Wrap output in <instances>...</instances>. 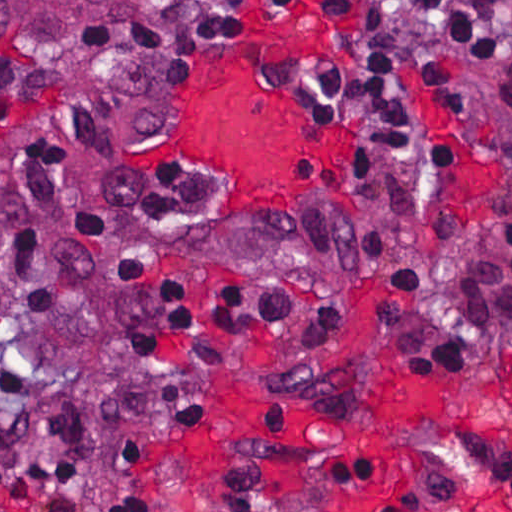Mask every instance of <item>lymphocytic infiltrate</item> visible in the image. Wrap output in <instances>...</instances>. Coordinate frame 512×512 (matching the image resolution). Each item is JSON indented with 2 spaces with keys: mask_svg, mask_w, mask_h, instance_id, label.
<instances>
[{
  "mask_svg": "<svg viewBox=\"0 0 512 512\" xmlns=\"http://www.w3.org/2000/svg\"><path fill=\"white\" fill-rule=\"evenodd\" d=\"M297 0H218L189 25L169 36L153 53L124 71L111 90L126 97L139 129H151L164 116L160 96L139 75L141 62H154L169 81H179L201 48L210 54L225 38H250L254 28L241 14L243 3L288 9ZM439 26L471 51L512 102V0H423ZM399 0H326L328 11L358 9L342 32L351 51L344 67L318 57H279L270 62L280 83L303 81L311 87L329 123L358 132L369 179L401 172L427 177L420 135L413 123L408 73L418 76L455 109L475 132L468 91L458 72L433 44L405 33L395 20ZM106 97L77 113L65 114L84 138L114 148L117 132L107 117ZM80 187L68 152L45 136H33L18 149L9 187L0 193V322L10 314L21 323L58 316L77 288L106 290L129 332L134 370L153 355L159 340L190 324L193 304L184 287L166 277L155 286L151 304L133 312L136 279L153 268V255L136 244L115 265L96 274L95 251L107 227L98 212L80 210L70 227L50 230L54 209L73 203ZM205 206V190L190 171L172 165L154 179L147 216L151 225L175 233ZM428 284L403 278L384 285L379 304L381 328L394 335L405 366L421 374H448L464 364V339L457 325L439 320ZM218 333H246L261 325L305 338H336L354 326L345 302H307L272 282L238 281L222 288L216 315ZM22 366L0 360V392L20 400L21 410L0 417V447L28 440L38 420L40 396ZM145 395V394H144ZM158 412L184 421L208 419L204 397L172 381L156 395H145ZM96 421L56 406L50 441L57 458L35 464L0 461V495L16 498L35 512H76L75 501L48 497L58 487L81 491L87 483V436ZM113 431V430H112ZM120 459L143 464L146 455L120 433ZM115 512H154L147 499L125 497Z\"/></svg>",
  "mask_w": 512,
  "mask_h": 512,
  "instance_id": "f902f5d3",
  "label": "lymphocytic infiltrate"
}]
</instances>
